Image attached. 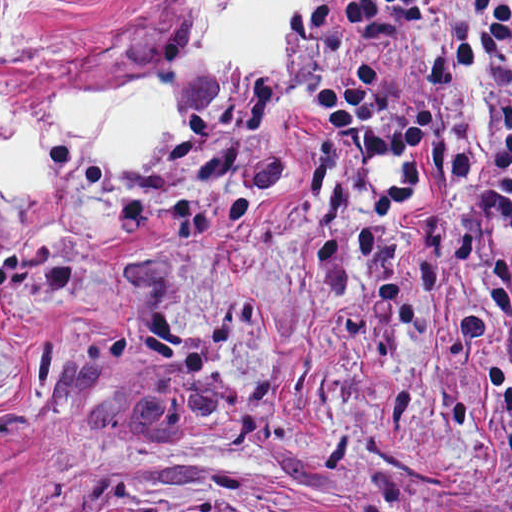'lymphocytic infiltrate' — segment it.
Instances as JSON below:
<instances>
[{"instance_id": "obj_1", "label": "lymphocytic infiltrate", "mask_w": 512, "mask_h": 512, "mask_svg": "<svg viewBox=\"0 0 512 512\" xmlns=\"http://www.w3.org/2000/svg\"><path fill=\"white\" fill-rule=\"evenodd\" d=\"M452 0H313L301 12L323 57L330 34L421 55ZM337 158L439 155L447 209L512 221V0H471L462 42L391 85L358 58L320 92Z\"/></svg>"}]
</instances>
